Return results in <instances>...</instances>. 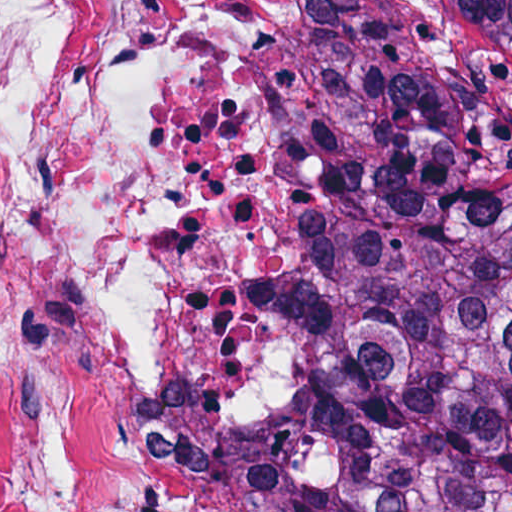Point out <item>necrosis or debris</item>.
Returning <instances> with one entry per match:
<instances>
[{"label":"necrosis or debris","instance_id":"1","mask_svg":"<svg viewBox=\"0 0 512 512\" xmlns=\"http://www.w3.org/2000/svg\"><path fill=\"white\" fill-rule=\"evenodd\" d=\"M309 0H0V512H179L273 408Z\"/></svg>","mask_w":512,"mask_h":512}]
</instances>
